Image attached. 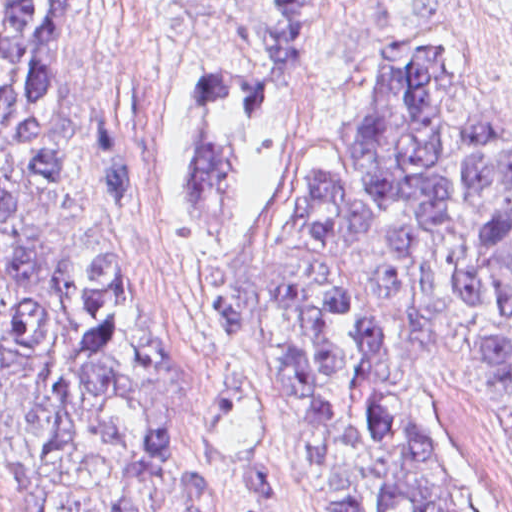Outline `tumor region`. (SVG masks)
<instances>
[{
    "label": "tumor region",
    "instance_id": "tumor-region-1",
    "mask_svg": "<svg viewBox=\"0 0 512 512\" xmlns=\"http://www.w3.org/2000/svg\"><path fill=\"white\" fill-rule=\"evenodd\" d=\"M353 1L144 0L207 222L182 300L210 335L247 329L230 246L254 153ZM90 2L0 0V422L25 512H260L198 438L188 362L143 266L61 241L83 165L58 87ZM260 258L317 511L470 512L406 414L441 367L512 399V114L487 39L409 55L388 116L301 171Z\"/></svg>",
    "mask_w": 512,
    "mask_h": 512
}]
</instances>
